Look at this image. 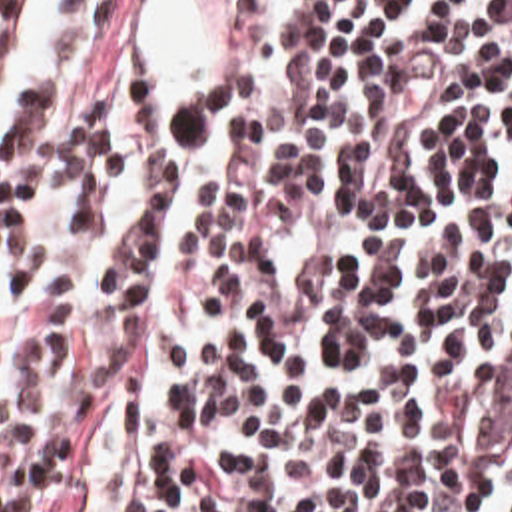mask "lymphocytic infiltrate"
Listing matches in <instances>:
<instances>
[{"mask_svg": "<svg viewBox=\"0 0 512 512\" xmlns=\"http://www.w3.org/2000/svg\"><path fill=\"white\" fill-rule=\"evenodd\" d=\"M140 2L0 144V512H512V0H240L196 102Z\"/></svg>", "mask_w": 512, "mask_h": 512, "instance_id": "obj_1", "label": "lymphocytic infiltrate"}]
</instances>
